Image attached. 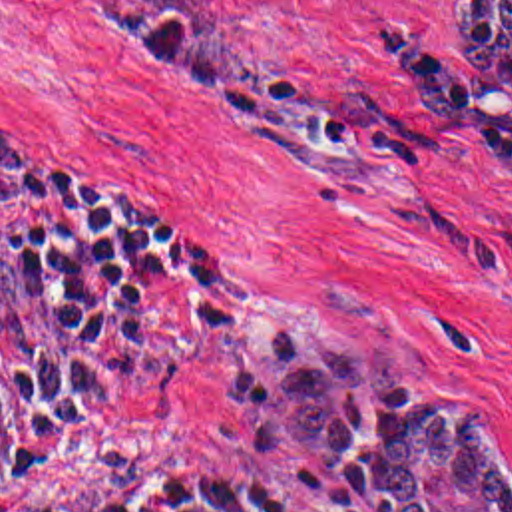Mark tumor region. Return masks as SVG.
I'll return each mask as SVG.
<instances>
[{"instance_id":"1","label":"tumor region","mask_w":512,"mask_h":512,"mask_svg":"<svg viewBox=\"0 0 512 512\" xmlns=\"http://www.w3.org/2000/svg\"><path fill=\"white\" fill-rule=\"evenodd\" d=\"M175 79L249 109L265 77L233 51L223 0H85ZM450 45L480 71V107L512 91V0H456ZM384 340L263 328L227 366L225 406L249 428L253 460L304 477L342 475L372 512H512V460L484 404L408 390Z\"/></svg>"}]
</instances>
